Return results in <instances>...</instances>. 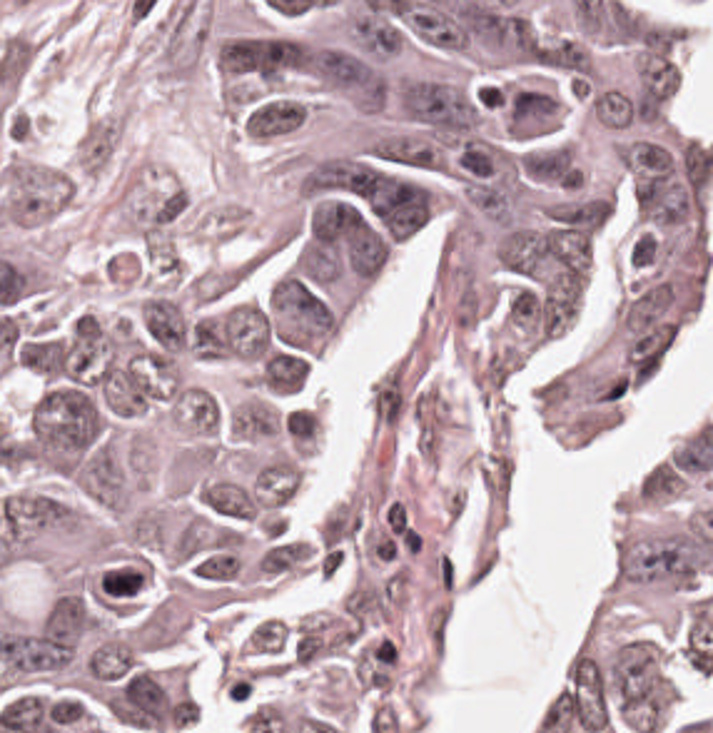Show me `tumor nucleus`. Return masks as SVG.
Segmentation results:
<instances>
[{
  "instance_id": "2f306a5c",
  "label": "tumor nucleus",
  "mask_w": 713,
  "mask_h": 733,
  "mask_svg": "<svg viewBox=\"0 0 713 733\" xmlns=\"http://www.w3.org/2000/svg\"><path fill=\"white\" fill-rule=\"evenodd\" d=\"M515 170L520 180L535 187L576 192L579 158L574 144L555 136L523 144Z\"/></svg>"
},
{
  "instance_id": "8643909e",
  "label": "tumor nucleus",
  "mask_w": 713,
  "mask_h": 733,
  "mask_svg": "<svg viewBox=\"0 0 713 733\" xmlns=\"http://www.w3.org/2000/svg\"><path fill=\"white\" fill-rule=\"evenodd\" d=\"M303 115L302 101L294 94L266 89L238 109V127L256 140H272L292 130Z\"/></svg>"
}]
</instances>
